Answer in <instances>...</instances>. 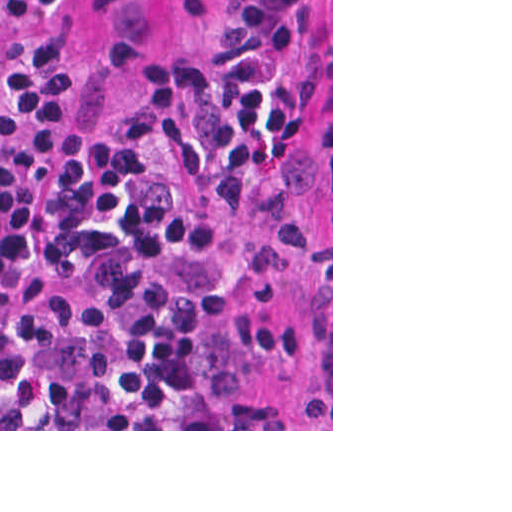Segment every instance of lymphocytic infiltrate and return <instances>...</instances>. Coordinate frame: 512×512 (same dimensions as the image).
Instances as JSON below:
<instances>
[{
	"instance_id": "lymphocytic-infiltrate-1",
	"label": "lymphocytic infiltrate",
	"mask_w": 512,
	"mask_h": 512,
	"mask_svg": "<svg viewBox=\"0 0 512 512\" xmlns=\"http://www.w3.org/2000/svg\"><path fill=\"white\" fill-rule=\"evenodd\" d=\"M0 0V429H298L223 356L216 284L254 215L302 0H219L130 111Z\"/></svg>"
}]
</instances>
